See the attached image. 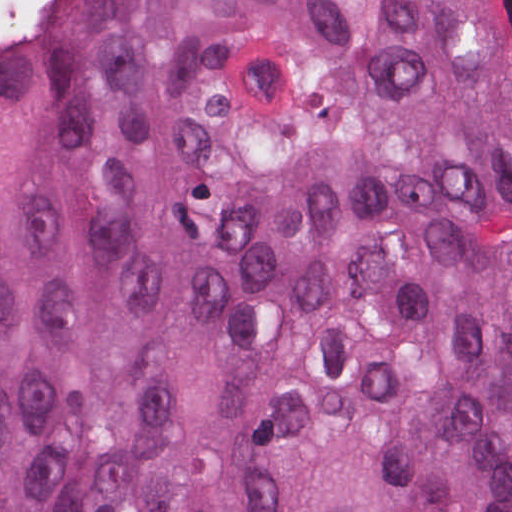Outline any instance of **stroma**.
Here are the masks:
<instances>
[{"label":"stroma","instance_id":"stroma-1","mask_svg":"<svg viewBox=\"0 0 512 512\" xmlns=\"http://www.w3.org/2000/svg\"><path fill=\"white\" fill-rule=\"evenodd\" d=\"M0 1H36L25 15L17 32L0 44V56L10 49L24 26L37 11L43 1H512V0H0Z\"/></svg>","mask_w":512,"mask_h":512}]
</instances>
